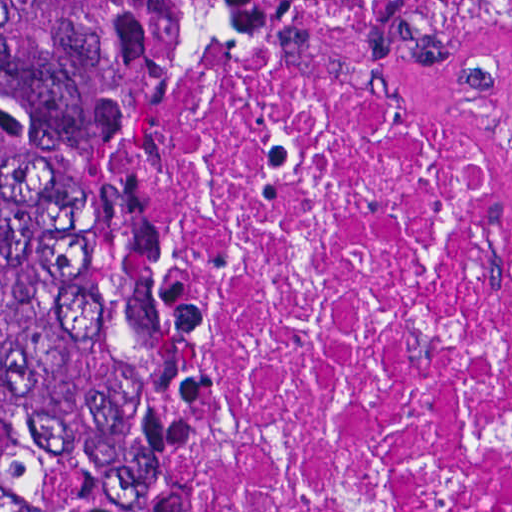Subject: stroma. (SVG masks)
Returning <instances> with one entry per match:
<instances>
[{"label":"stroma","instance_id":"35a3bbf8","mask_svg":"<svg viewBox=\"0 0 512 512\" xmlns=\"http://www.w3.org/2000/svg\"><path fill=\"white\" fill-rule=\"evenodd\" d=\"M181 39L182 38L172 39L154 77L152 78V80L142 98V168H143V163H144V159H145V155H146L148 140H149V137L152 132L154 108H155V97H156L158 78H159L160 72L162 70V67H163L165 61L167 60L169 54L172 52V50L175 48V46L181 41ZM142 239L148 249L146 235H145L144 222H143V216H142Z\"/></svg>","mask_w":512,"mask_h":512}]
</instances>
